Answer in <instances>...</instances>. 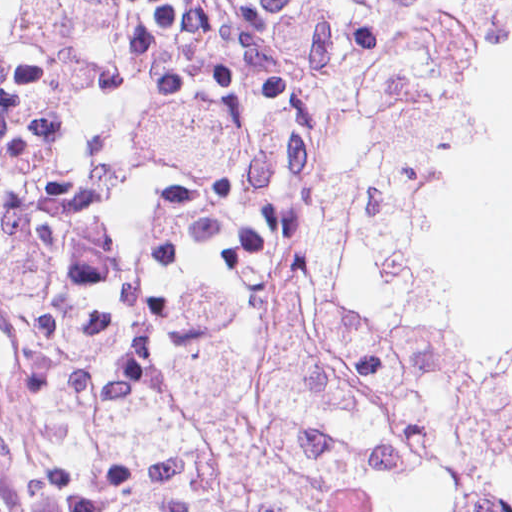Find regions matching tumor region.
I'll use <instances>...</instances> for the list:
<instances>
[{
	"instance_id": "obj_1",
	"label": "tumor region",
	"mask_w": 512,
	"mask_h": 512,
	"mask_svg": "<svg viewBox=\"0 0 512 512\" xmlns=\"http://www.w3.org/2000/svg\"><path fill=\"white\" fill-rule=\"evenodd\" d=\"M487 51L465 18L394 26L324 95L219 303L86 355L77 397L129 511L315 512L418 473L447 512H512V345L416 314L390 263Z\"/></svg>"
}]
</instances>
